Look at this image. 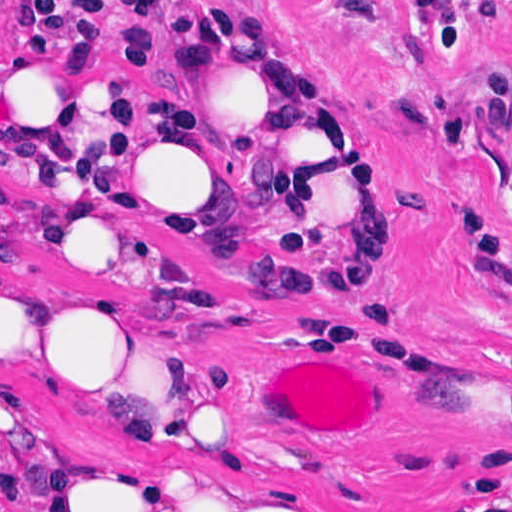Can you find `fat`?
Here are the masks:
<instances>
[{"instance_id":"1","label":"fat","mask_w":512,"mask_h":512,"mask_svg":"<svg viewBox=\"0 0 512 512\" xmlns=\"http://www.w3.org/2000/svg\"><path fill=\"white\" fill-rule=\"evenodd\" d=\"M219 181L292 189L308 283L387 304L391 260L324 72L262 8L190 25L184 130L137 74L29 0L1 22V206L17 246L139 279L202 258ZM142 300V299H141ZM116 294H53L46 365L90 426L137 446L64 455L41 512H301L216 454L255 432L245 393L194 369L173 317Z\"/></svg>"}]
</instances>
